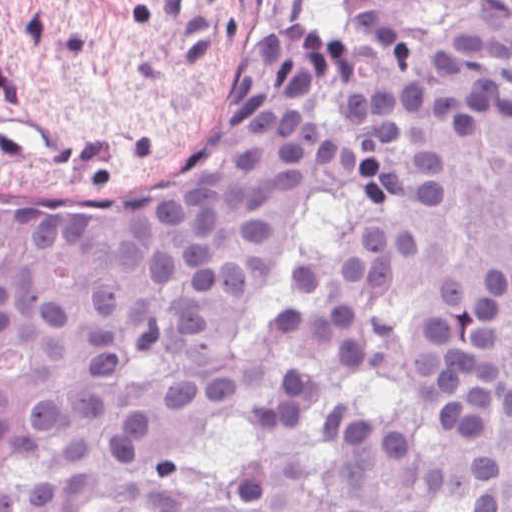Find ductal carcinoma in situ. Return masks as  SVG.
Segmentation results:
<instances>
[{"label": "ductal carcinoma in situ", "instance_id": "ductal-carcinoma-in-situ-1", "mask_svg": "<svg viewBox=\"0 0 512 512\" xmlns=\"http://www.w3.org/2000/svg\"><path fill=\"white\" fill-rule=\"evenodd\" d=\"M0 512H512V0H356L124 195L0 192Z\"/></svg>", "mask_w": 512, "mask_h": 512}]
</instances>
